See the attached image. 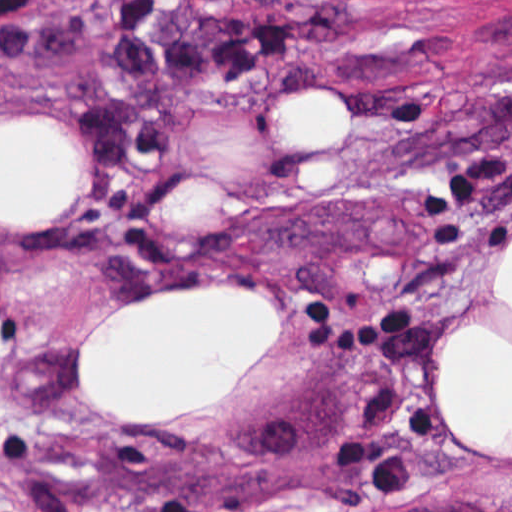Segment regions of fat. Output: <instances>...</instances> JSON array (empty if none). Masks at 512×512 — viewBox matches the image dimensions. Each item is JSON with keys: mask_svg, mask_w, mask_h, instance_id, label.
Instances as JSON below:
<instances>
[{"mask_svg": "<svg viewBox=\"0 0 512 512\" xmlns=\"http://www.w3.org/2000/svg\"><path fill=\"white\" fill-rule=\"evenodd\" d=\"M312 84L278 114L284 146L326 151L347 141L340 103ZM52 119L0 123V226L57 213L83 167L81 142ZM160 292L100 320L76 356L79 382L119 427L185 409L235 385L276 329L274 295ZM431 411L439 428L512 460V246L496 298L450 327L432 355Z\"/></svg>", "mask_w": 512, "mask_h": 512, "instance_id": "obj_1", "label": "fat"}]
</instances>
